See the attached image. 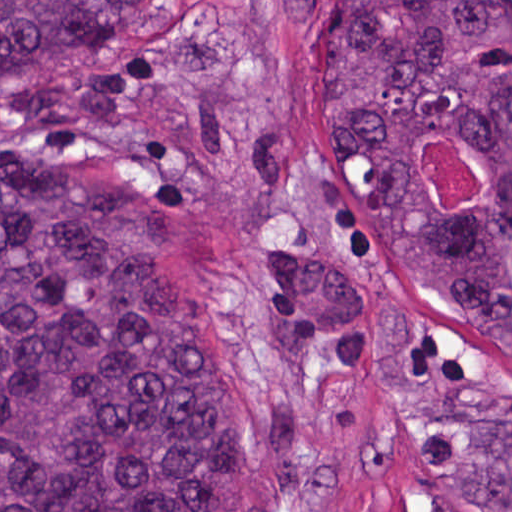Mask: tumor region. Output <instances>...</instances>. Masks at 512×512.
<instances>
[{
    "instance_id": "1",
    "label": "tumor region",
    "mask_w": 512,
    "mask_h": 512,
    "mask_svg": "<svg viewBox=\"0 0 512 512\" xmlns=\"http://www.w3.org/2000/svg\"><path fill=\"white\" fill-rule=\"evenodd\" d=\"M183 1L0 0V80ZM318 119L419 283L512 355V0H344ZM438 129L485 174L467 213L417 169ZM264 306L266 416L162 197L79 163L1 165L0 512H269L375 477V444L305 427L316 352L359 368L364 316L467 498L512 512V368L432 325L375 247L273 246Z\"/></svg>"
}]
</instances>
